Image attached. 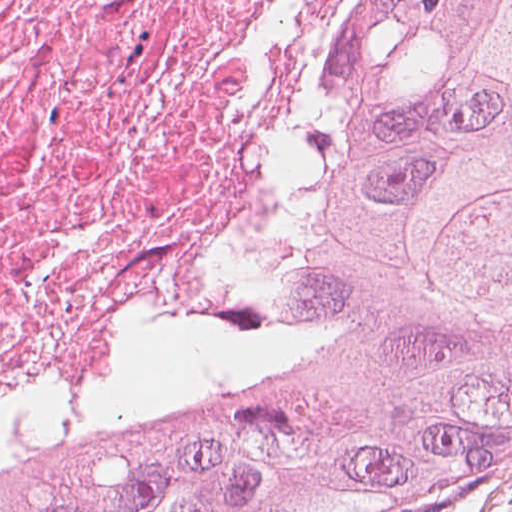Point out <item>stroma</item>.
I'll list each match as a JSON object with an SVG mask.
<instances>
[{
  "label": "stroma",
  "instance_id": "1",
  "mask_svg": "<svg viewBox=\"0 0 512 512\" xmlns=\"http://www.w3.org/2000/svg\"><path fill=\"white\" fill-rule=\"evenodd\" d=\"M392 512H512V489L486 499L450 498L426 507Z\"/></svg>",
  "mask_w": 512,
  "mask_h": 512
}]
</instances>
